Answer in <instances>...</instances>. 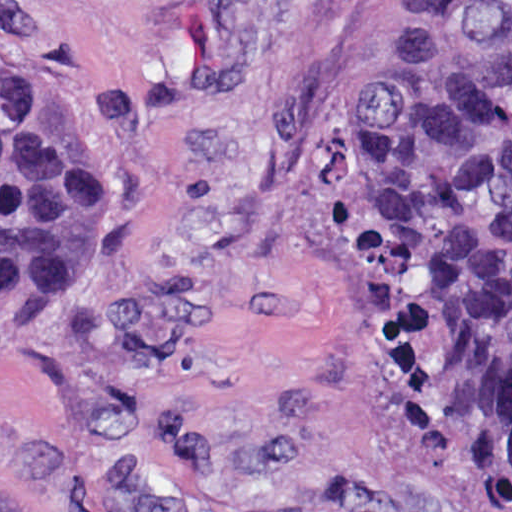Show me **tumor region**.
I'll use <instances>...</instances> for the list:
<instances>
[{
    "label": "tumor region",
    "mask_w": 512,
    "mask_h": 512,
    "mask_svg": "<svg viewBox=\"0 0 512 512\" xmlns=\"http://www.w3.org/2000/svg\"><path fill=\"white\" fill-rule=\"evenodd\" d=\"M352 233L408 450L512 498V0H352ZM93 250L94 157L1 66V297L64 290Z\"/></svg>",
    "instance_id": "e687c5a6"
}]
</instances>
